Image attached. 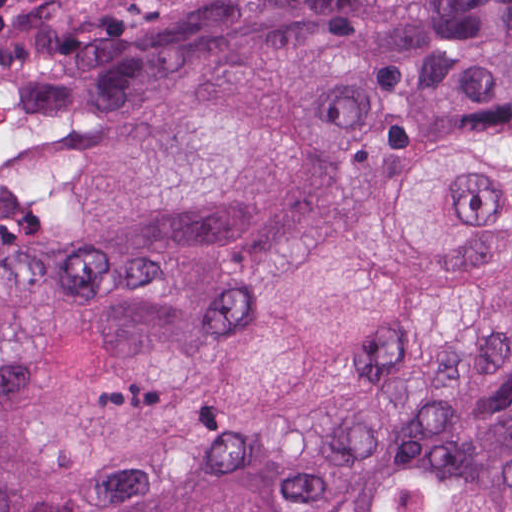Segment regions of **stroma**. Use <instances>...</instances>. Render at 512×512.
I'll list each match as a JSON object with an SVG mask.
<instances>
[{
    "label": "stroma",
    "instance_id": "stroma-1",
    "mask_svg": "<svg viewBox=\"0 0 512 512\" xmlns=\"http://www.w3.org/2000/svg\"><path fill=\"white\" fill-rule=\"evenodd\" d=\"M77 0H9L4 4V36L0 38V85L30 36ZM0 89V124L3 112Z\"/></svg>",
    "mask_w": 512,
    "mask_h": 512
}]
</instances>
